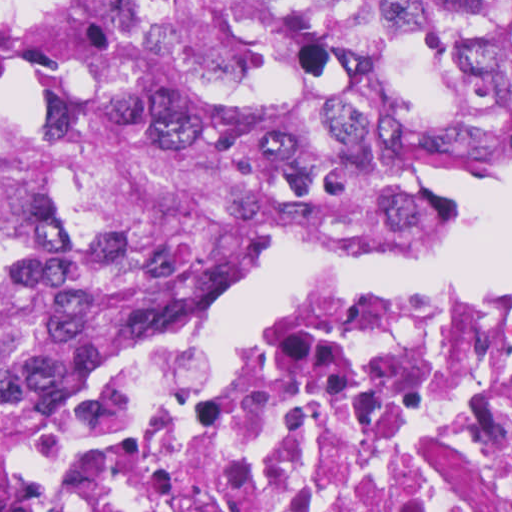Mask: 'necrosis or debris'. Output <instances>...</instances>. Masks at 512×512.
Listing matches in <instances>:
<instances>
[{
  "instance_id": "4bbe7bcc",
  "label": "necrosis or debris",
  "mask_w": 512,
  "mask_h": 512,
  "mask_svg": "<svg viewBox=\"0 0 512 512\" xmlns=\"http://www.w3.org/2000/svg\"><path fill=\"white\" fill-rule=\"evenodd\" d=\"M92 368L3 512H512V280Z\"/></svg>"
}]
</instances>
